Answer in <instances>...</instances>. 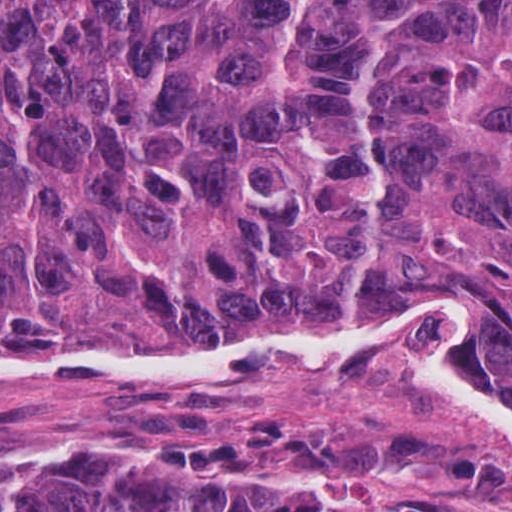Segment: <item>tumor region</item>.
I'll list each match as a JSON object with an SVG mask.
<instances>
[{
    "label": "tumor region",
    "mask_w": 512,
    "mask_h": 512,
    "mask_svg": "<svg viewBox=\"0 0 512 512\" xmlns=\"http://www.w3.org/2000/svg\"><path fill=\"white\" fill-rule=\"evenodd\" d=\"M482 290L512 401V0H0V338L214 350ZM237 469L424 476L512 512V465L424 428L264 410L138 461L0 471V512H364Z\"/></svg>",
    "instance_id": "obj_1"
}]
</instances>
